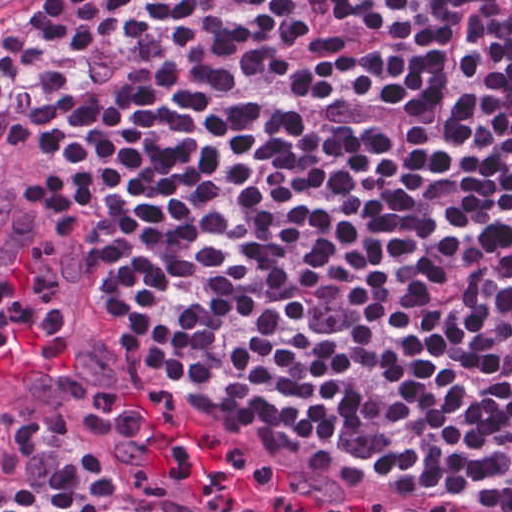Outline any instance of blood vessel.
Masks as SVG:
<instances>
[{
  "label": "blood vessel",
  "instance_id": "8fb6f2fc",
  "mask_svg": "<svg viewBox=\"0 0 512 512\" xmlns=\"http://www.w3.org/2000/svg\"><path fill=\"white\" fill-rule=\"evenodd\" d=\"M30 0H0V21ZM44 274L59 282L57 305L38 328L0 350V390H26L47 379L76 346L82 295L73 270L54 251L0 236V291L25 299Z\"/></svg>",
  "mask_w": 512,
  "mask_h": 512
}]
</instances>
